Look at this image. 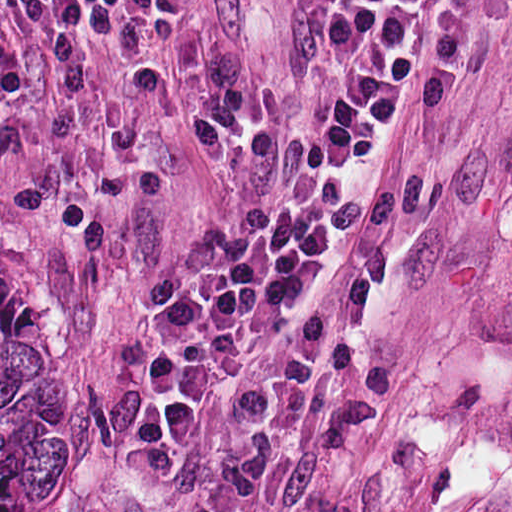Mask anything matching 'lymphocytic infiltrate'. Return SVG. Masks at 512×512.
Listing matches in <instances>:
<instances>
[{
	"label": "lymphocytic infiltrate",
	"instance_id": "f902f5d3",
	"mask_svg": "<svg viewBox=\"0 0 512 512\" xmlns=\"http://www.w3.org/2000/svg\"><path fill=\"white\" fill-rule=\"evenodd\" d=\"M319 170L297 202L227 208L166 263L165 316L127 404L123 455L135 475L177 477L197 420L228 409L270 377L290 383L322 367L334 329L327 304L305 309L273 345L253 327L298 280L317 274L349 172L407 106L409 61L438 0H318ZM45 37L100 19L170 26L184 0H8Z\"/></svg>",
	"mask_w": 512,
	"mask_h": 512
}]
</instances>
